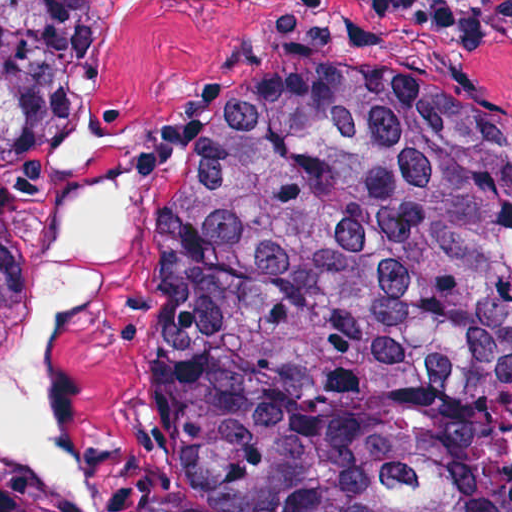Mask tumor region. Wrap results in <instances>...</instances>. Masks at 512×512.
<instances>
[{"label":"tumor region","instance_id":"obj_1","mask_svg":"<svg viewBox=\"0 0 512 512\" xmlns=\"http://www.w3.org/2000/svg\"><path fill=\"white\" fill-rule=\"evenodd\" d=\"M119 0H0V341ZM158 512H470L512 381V132L409 80L204 91L148 224ZM0 512H52L0 481Z\"/></svg>","mask_w":512,"mask_h":512}]
</instances>
